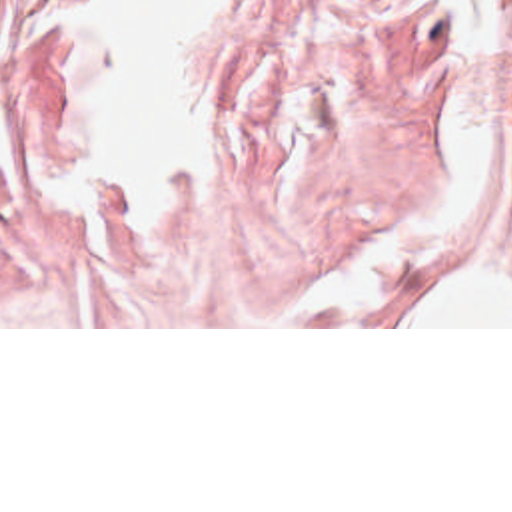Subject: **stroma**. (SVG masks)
<instances>
[{"mask_svg":"<svg viewBox=\"0 0 512 512\" xmlns=\"http://www.w3.org/2000/svg\"><path fill=\"white\" fill-rule=\"evenodd\" d=\"M0 8V329L300 327L417 187L435 133L443 0H214L192 187L76 203L62 10ZM495 139L512 151V0Z\"/></svg>","mask_w":512,"mask_h":512,"instance_id":"stroma-1","label":"stroma"}]
</instances>
